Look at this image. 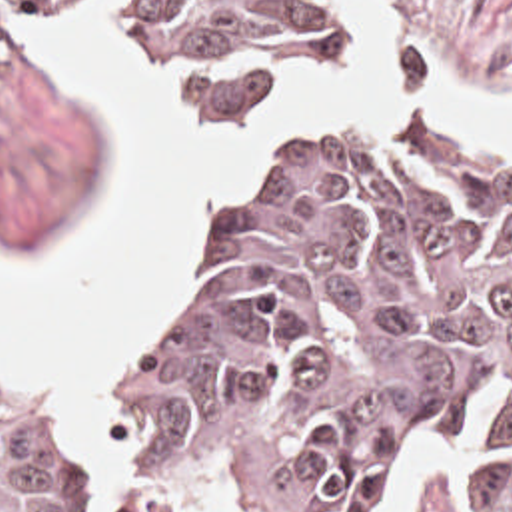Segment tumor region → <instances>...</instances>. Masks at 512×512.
I'll return each mask as SVG.
<instances>
[{
    "instance_id": "e687c5a6",
    "label": "tumor region",
    "mask_w": 512,
    "mask_h": 512,
    "mask_svg": "<svg viewBox=\"0 0 512 512\" xmlns=\"http://www.w3.org/2000/svg\"><path fill=\"white\" fill-rule=\"evenodd\" d=\"M107 14L221 106H285L341 62L345 0H31ZM11 2L0 0V48ZM123 478L0 398V512H371L385 460L455 440L463 512H512V152L445 110L223 184L175 314L107 394Z\"/></svg>"
}]
</instances>
